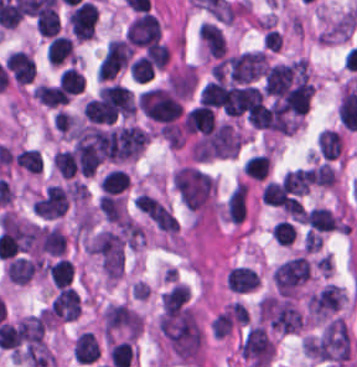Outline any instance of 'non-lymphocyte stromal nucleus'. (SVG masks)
<instances>
[{
  "label": "non-lymphocyte stromal nucleus",
  "instance_id": "dd21d789",
  "mask_svg": "<svg viewBox=\"0 0 357 367\" xmlns=\"http://www.w3.org/2000/svg\"><path fill=\"white\" fill-rule=\"evenodd\" d=\"M246 213V185L237 182L226 201V216L234 222H241Z\"/></svg>",
  "mask_w": 357,
  "mask_h": 367
}]
</instances>
